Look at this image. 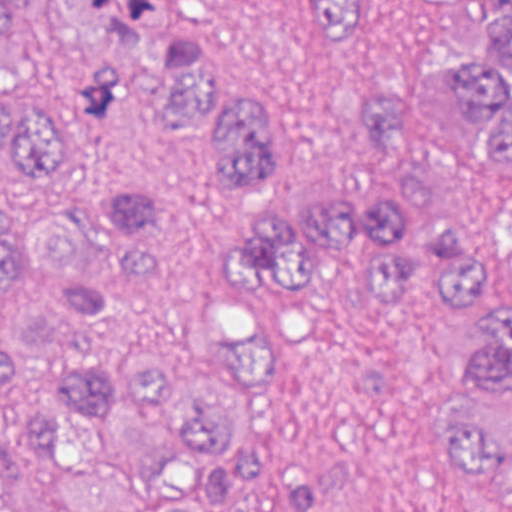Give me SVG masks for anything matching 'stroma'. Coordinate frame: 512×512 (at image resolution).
Returning <instances> with one entry per match:
<instances>
[{"label": "stroma", "instance_id": "35a3bbf8", "mask_svg": "<svg viewBox=\"0 0 512 512\" xmlns=\"http://www.w3.org/2000/svg\"><path fill=\"white\" fill-rule=\"evenodd\" d=\"M495 1L382 0L345 54L310 30L313 0H157V33L201 41L217 79L272 112L260 191L242 195L219 191L216 132L160 121L168 81L150 66L131 70L119 109L98 117L80 106L79 84L106 53L49 0L28 10L0 90L65 129L76 168L46 191L0 175V221L91 229L92 267L76 285H113L124 251L103 196L117 182L150 188L181 214L190 311L259 334L262 349L238 415L262 441L263 476L227 492L225 512H512V482L453 464L456 422L487 398L466 372L477 326L448 287L396 303L370 287L367 255L350 252L306 296L269 300L226 287L217 259L235 211L261 197H366L402 170L446 168L424 147L370 132L361 98L466 61ZM69 286L17 266L0 288V320H31Z\"/></svg>", "mask_w": 512, "mask_h": 512}]
</instances>
